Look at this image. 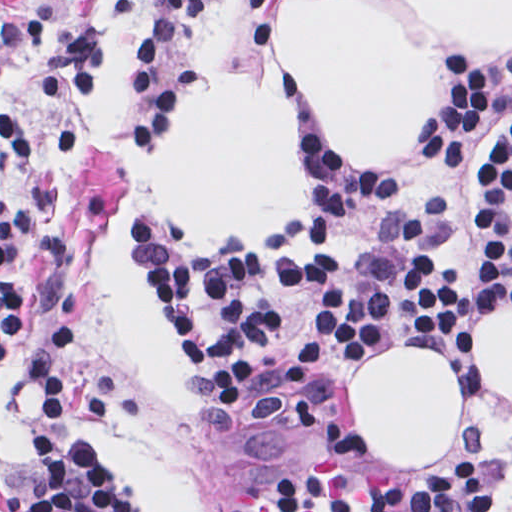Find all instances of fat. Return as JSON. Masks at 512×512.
Masks as SVG:
<instances>
[{
    "label": "fat",
    "instance_id": "1",
    "mask_svg": "<svg viewBox=\"0 0 512 512\" xmlns=\"http://www.w3.org/2000/svg\"><path fill=\"white\" fill-rule=\"evenodd\" d=\"M410 5L426 29L512 46V1ZM277 60L357 169L412 153L437 103L435 61L391 1H277ZM152 182L180 223L209 235H272L314 200L294 101L242 80L208 81L177 116ZM137 236L123 201L100 247L109 300L144 379L174 408L204 410L186 380V356L126 251ZM393 344L351 372L349 398L383 464L430 468L460 442L465 386L435 350ZM470 360L512 401V304L474 325Z\"/></svg>",
    "mask_w": 512,
    "mask_h": 512
}]
</instances>
